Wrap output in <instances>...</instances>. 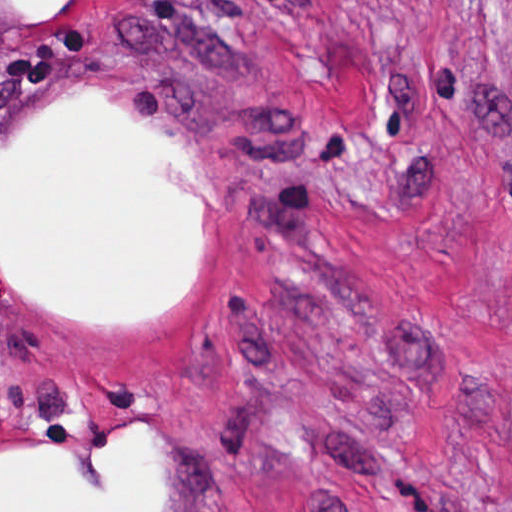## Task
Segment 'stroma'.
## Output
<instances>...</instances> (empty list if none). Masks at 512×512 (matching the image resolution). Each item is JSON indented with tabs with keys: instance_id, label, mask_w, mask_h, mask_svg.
Returning a JSON list of instances; mask_svg holds the SVG:
<instances>
[{
	"instance_id": "stroma-1",
	"label": "stroma",
	"mask_w": 512,
	"mask_h": 512,
	"mask_svg": "<svg viewBox=\"0 0 512 512\" xmlns=\"http://www.w3.org/2000/svg\"><path fill=\"white\" fill-rule=\"evenodd\" d=\"M100 101L185 158V283L93 319L1 269V178ZM147 512H512V0H0L1 450Z\"/></svg>"
}]
</instances>
